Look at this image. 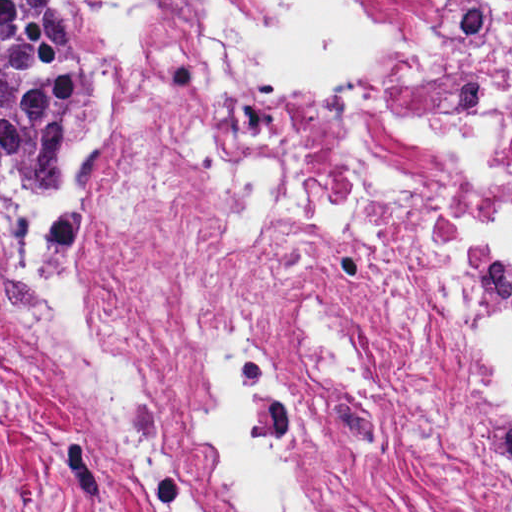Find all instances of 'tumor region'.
<instances>
[{"label": "tumor region", "mask_w": 512, "mask_h": 512, "mask_svg": "<svg viewBox=\"0 0 512 512\" xmlns=\"http://www.w3.org/2000/svg\"><path fill=\"white\" fill-rule=\"evenodd\" d=\"M95 111V46L69 0H0V127L30 191L75 207V167Z\"/></svg>", "instance_id": "tumor-region-1"}]
</instances>
